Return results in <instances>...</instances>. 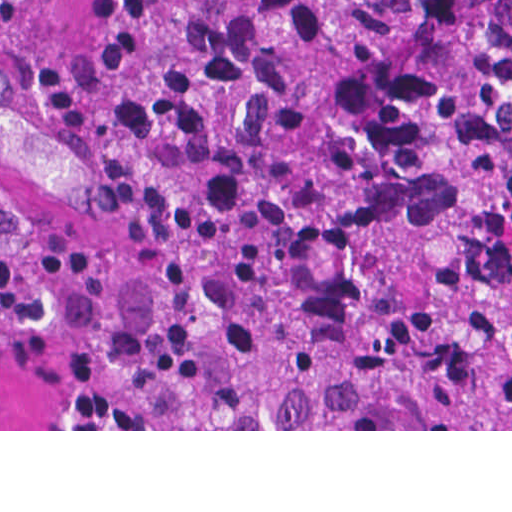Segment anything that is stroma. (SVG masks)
Here are the masks:
<instances>
[{
	"instance_id": "stroma-1",
	"label": "stroma",
	"mask_w": 512,
	"mask_h": 512,
	"mask_svg": "<svg viewBox=\"0 0 512 512\" xmlns=\"http://www.w3.org/2000/svg\"><path fill=\"white\" fill-rule=\"evenodd\" d=\"M0 244L43 311L0 324V431H512L164 429L131 405L95 346L143 259L145 193L90 65V0H0Z\"/></svg>"
}]
</instances>
